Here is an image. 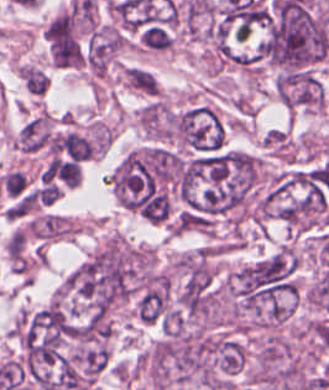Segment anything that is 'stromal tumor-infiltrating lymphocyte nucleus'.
Returning a JSON list of instances; mask_svg holds the SVG:
<instances>
[{"mask_svg": "<svg viewBox=\"0 0 329 390\" xmlns=\"http://www.w3.org/2000/svg\"><path fill=\"white\" fill-rule=\"evenodd\" d=\"M140 46L154 51L169 50L174 44L171 30L158 22H150L144 26L140 38Z\"/></svg>", "mask_w": 329, "mask_h": 390, "instance_id": "bc302bb0", "label": "stromal tumor-infiltrating lymphocyte nucleus"}, {"mask_svg": "<svg viewBox=\"0 0 329 390\" xmlns=\"http://www.w3.org/2000/svg\"><path fill=\"white\" fill-rule=\"evenodd\" d=\"M0 187L4 194L20 197L29 187V180L21 170L9 169L0 179Z\"/></svg>", "mask_w": 329, "mask_h": 390, "instance_id": "52c7bb5b", "label": "stromal tumor-infiltrating lymphocyte nucleus"}, {"mask_svg": "<svg viewBox=\"0 0 329 390\" xmlns=\"http://www.w3.org/2000/svg\"><path fill=\"white\" fill-rule=\"evenodd\" d=\"M325 175H326V165L316 169V181L325 184Z\"/></svg>", "mask_w": 329, "mask_h": 390, "instance_id": "3290ff9b", "label": "stromal tumor-infiltrating lymphocyte nucleus"}]
</instances>
